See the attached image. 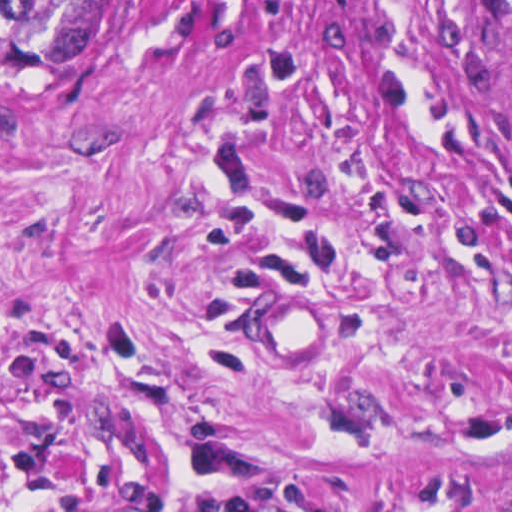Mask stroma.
Wrapping results in <instances>:
<instances>
[{"label": "stroma", "mask_w": 512, "mask_h": 512, "mask_svg": "<svg viewBox=\"0 0 512 512\" xmlns=\"http://www.w3.org/2000/svg\"><path fill=\"white\" fill-rule=\"evenodd\" d=\"M340 302L309 368L253 286ZM0 512H512V57L480 0H118L1 68Z\"/></svg>", "instance_id": "obj_1"}]
</instances>
